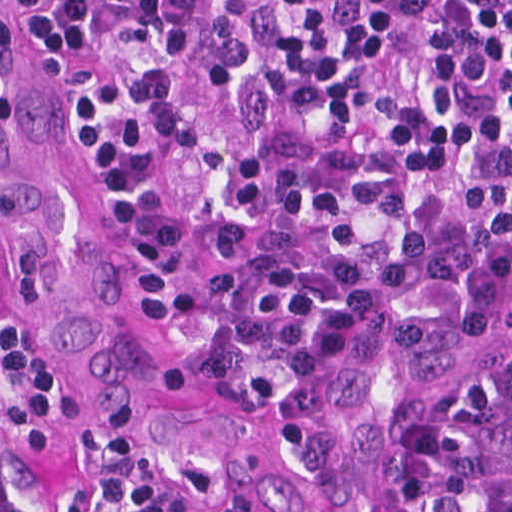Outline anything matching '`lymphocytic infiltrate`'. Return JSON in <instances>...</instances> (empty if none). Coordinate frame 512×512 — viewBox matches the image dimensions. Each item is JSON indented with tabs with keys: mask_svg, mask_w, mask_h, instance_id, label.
<instances>
[{
	"mask_svg": "<svg viewBox=\"0 0 512 512\" xmlns=\"http://www.w3.org/2000/svg\"><path fill=\"white\" fill-rule=\"evenodd\" d=\"M156 324L259 383L512 268V0H40ZM76 384L0 251V438L73 433ZM0 512H234L119 436L83 491ZM374 512H512V350L382 458Z\"/></svg>",
	"mask_w": 512,
	"mask_h": 512,
	"instance_id": "f902f5d3",
	"label": "lymphocytic infiltrate"
}]
</instances>
